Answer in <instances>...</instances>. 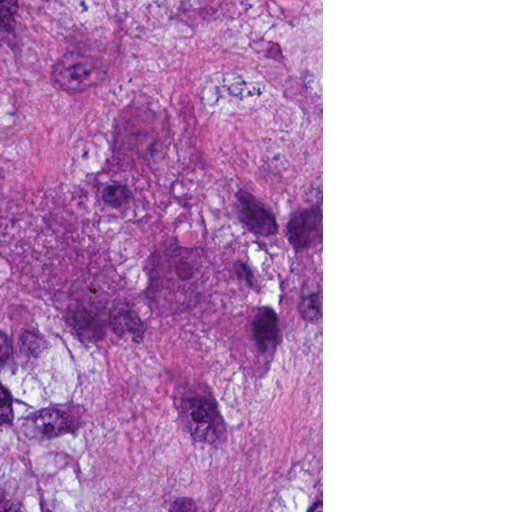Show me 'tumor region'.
<instances>
[{"mask_svg": "<svg viewBox=\"0 0 512 512\" xmlns=\"http://www.w3.org/2000/svg\"><path fill=\"white\" fill-rule=\"evenodd\" d=\"M0 512H161V0H0Z\"/></svg>", "mask_w": 512, "mask_h": 512, "instance_id": "e687c5a6", "label": "tumor region"}]
</instances>
